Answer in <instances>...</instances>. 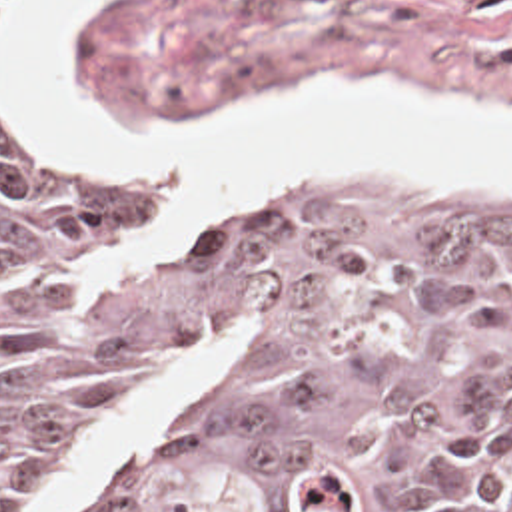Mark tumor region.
Wrapping results in <instances>:
<instances>
[{
    "label": "tumor region",
    "mask_w": 512,
    "mask_h": 512,
    "mask_svg": "<svg viewBox=\"0 0 512 512\" xmlns=\"http://www.w3.org/2000/svg\"><path fill=\"white\" fill-rule=\"evenodd\" d=\"M154 223L0 123V512L238 317L184 424L80 512H512V215L294 185L128 263Z\"/></svg>",
    "instance_id": "e687c5a6"
}]
</instances>
